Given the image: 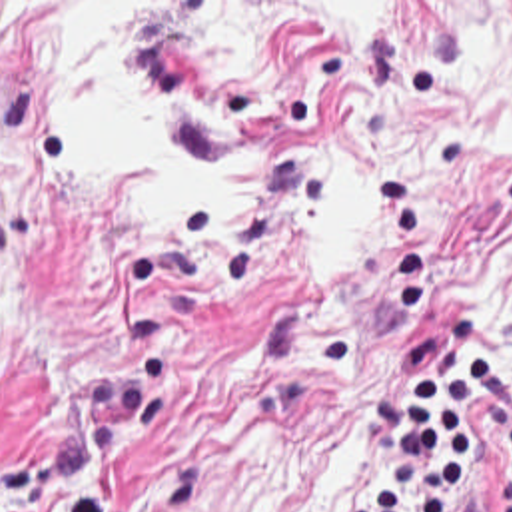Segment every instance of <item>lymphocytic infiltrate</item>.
I'll use <instances>...</instances> for the list:
<instances>
[{"mask_svg":"<svg viewBox=\"0 0 512 512\" xmlns=\"http://www.w3.org/2000/svg\"><path fill=\"white\" fill-rule=\"evenodd\" d=\"M397 375L369 403L383 447L347 512H449L471 485V425L511 431V455L499 477V512H512V373L477 347L447 363L439 335L391 343Z\"/></svg>","mask_w":512,"mask_h":512,"instance_id":"lymphocytic-infiltrate-1","label":"lymphocytic infiltrate"}]
</instances>
